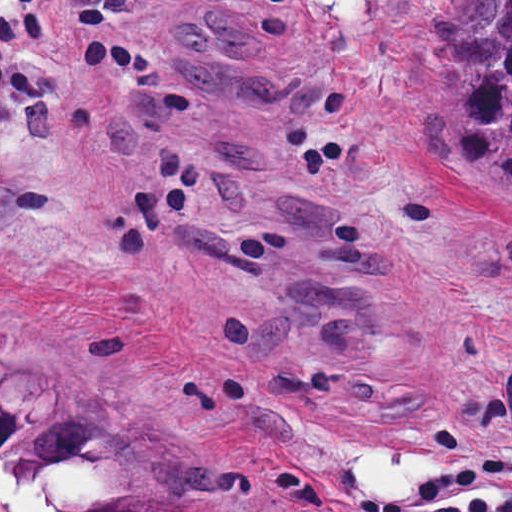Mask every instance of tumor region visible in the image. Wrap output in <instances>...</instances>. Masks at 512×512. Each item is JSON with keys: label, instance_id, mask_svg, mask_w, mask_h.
<instances>
[{"label": "tumor region", "instance_id": "obj_1", "mask_svg": "<svg viewBox=\"0 0 512 512\" xmlns=\"http://www.w3.org/2000/svg\"><path fill=\"white\" fill-rule=\"evenodd\" d=\"M455 161L483 228L512 231V0H461L450 57ZM238 468L138 437L0 341V512H217Z\"/></svg>", "mask_w": 512, "mask_h": 512}]
</instances>
